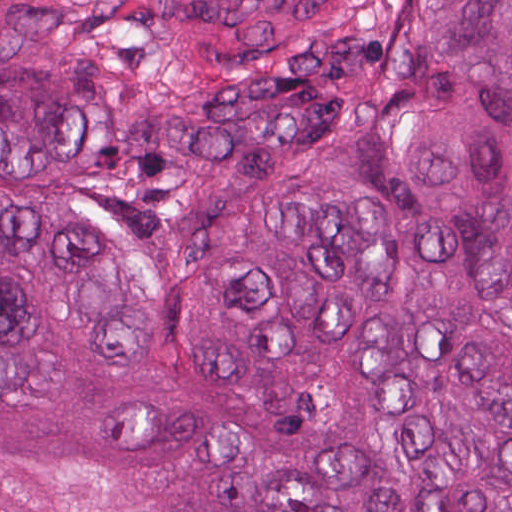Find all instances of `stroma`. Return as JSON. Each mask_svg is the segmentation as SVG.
I'll return each mask as SVG.
<instances>
[{"label":"stroma","instance_id":"obj_1","mask_svg":"<svg viewBox=\"0 0 512 512\" xmlns=\"http://www.w3.org/2000/svg\"><path fill=\"white\" fill-rule=\"evenodd\" d=\"M1 1H512V0H0V512H1Z\"/></svg>","mask_w":512,"mask_h":512}]
</instances>
